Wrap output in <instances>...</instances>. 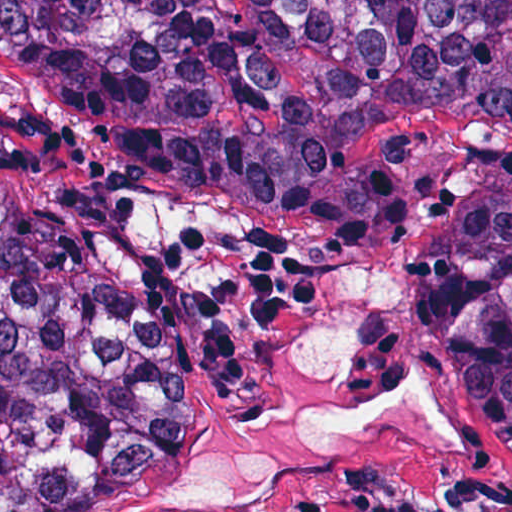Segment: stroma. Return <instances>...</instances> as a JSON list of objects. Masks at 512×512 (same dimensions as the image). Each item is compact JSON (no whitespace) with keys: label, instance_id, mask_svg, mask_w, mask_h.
Segmentation results:
<instances>
[{"label":"stroma","instance_id":"stroma-1","mask_svg":"<svg viewBox=\"0 0 512 512\" xmlns=\"http://www.w3.org/2000/svg\"><path fill=\"white\" fill-rule=\"evenodd\" d=\"M425 249L424 211H409L377 251L344 262L313 286L291 325L241 330L252 364L250 389L225 393L208 368L193 367L176 438L157 461L130 476L119 512L177 444L215 439L282 404L289 389V332L323 286L350 262H383L399 271L402 285L367 329L361 390L380 399L419 377L444 409L450 428L441 442H424L388 426L360 429L278 495L225 502L205 512H512V461L471 418L449 339L410 303Z\"/></svg>","mask_w":512,"mask_h":512}]
</instances>
